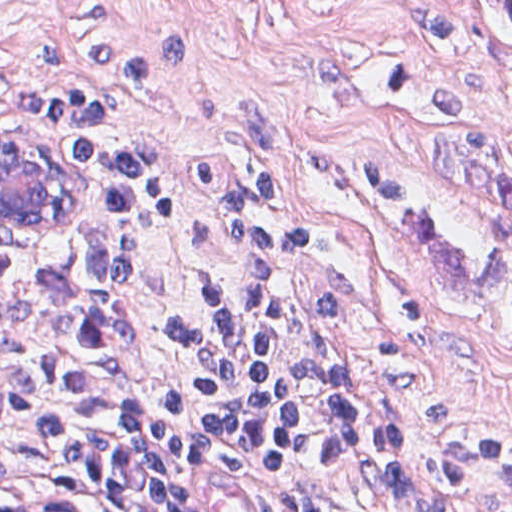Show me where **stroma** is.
Returning a JSON list of instances; mask_svg holds the SVG:
<instances>
[{"label":"stroma","mask_w":512,"mask_h":512,"mask_svg":"<svg viewBox=\"0 0 512 512\" xmlns=\"http://www.w3.org/2000/svg\"><path fill=\"white\" fill-rule=\"evenodd\" d=\"M0 56L146 143L158 212H116L73 177L48 216L0 210V270L169 232L145 279L150 397L207 377L200 313L239 268L235 204L264 201L299 286L285 384L417 474L512 456V224L426 158L464 127L512 170V22L487 0H0ZM15 476L63 512H146L90 478ZM428 512H512V460Z\"/></svg>","instance_id":"35a3bbf8"}]
</instances>
